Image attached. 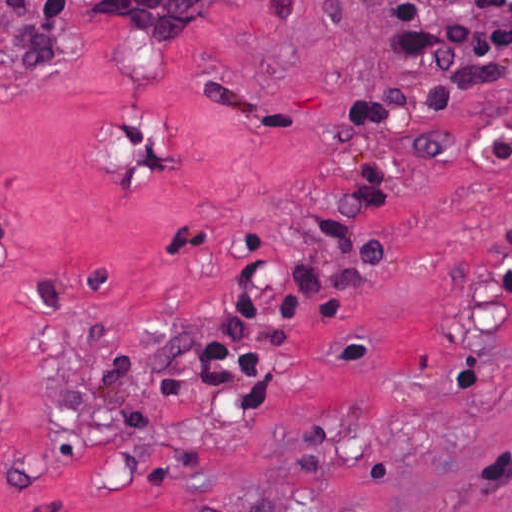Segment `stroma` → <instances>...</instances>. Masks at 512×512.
I'll return each instance as SVG.
<instances>
[{"mask_svg": "<svg viewBox=\"0 0 512 512\" xmlns=\"http://www.w3.org/2000/svg\"><path fill=\"white\" fill-rule=\"evenodd\" d=\"M43 1L0 0V512H512V84L355 136L389 57L363 0H217L183 38ZM430 133L451 152L402 158L291 393L308 306L271 391L201 385L240 263L304 257L372 154Z\"/></svg>", "mask_w": 512, "mask_h": 512, "instance_id": "35a3bbf8", "label": "stroma"}]
</instances>
